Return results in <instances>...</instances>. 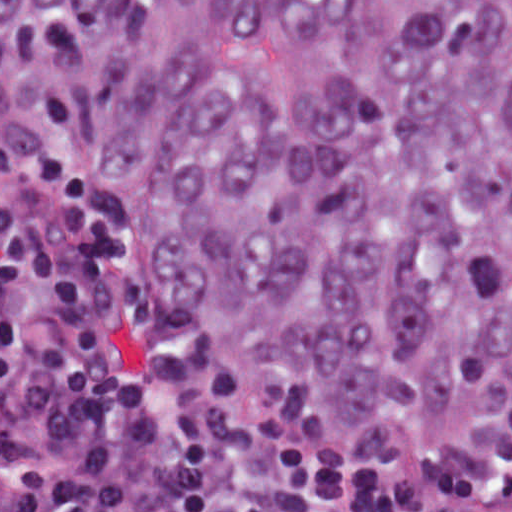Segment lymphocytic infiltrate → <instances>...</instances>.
I'll return each mask as SVG.
<instances>
[{"instance_id": "lymphocytic-infiltrate-1", "label": "lymphocytic infiltrate", "mask_w": 512, "mask_h": 512, "mask_svg": "<svg viewBox=\"0 0 512 512\" xmlns=\"http://www.w3.org/2000/svg\"><path fill=\"white\" fill-rule=\"evenodd\" d=\"M0 512H512V412L364 458L211 337L0 96Z\"/></svg>"}]
</instances>
